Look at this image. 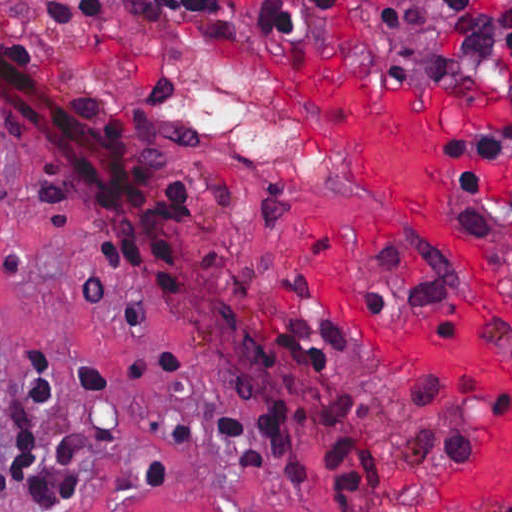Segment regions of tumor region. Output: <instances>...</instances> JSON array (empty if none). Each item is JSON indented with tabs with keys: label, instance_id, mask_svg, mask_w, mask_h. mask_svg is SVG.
Returning a JSON list of instances; mask_svg holds the SVG:
<instances>
[{
	"label": "tumor region",
	"instance_id": "1",
	"mask_svg": "<svg viewBox=\"0 0 512 512\" xmlns=\"http://www.w3.org/2000/svg\"><path fill=\"white\" fill-rule=\"evenodd\" d=\"M388 1L402 41L439 47L467 75L503 71L512 39V0Z\"/></svg>",
	"mask_w": 512,
	"mask_h": 512
}]
</instances>
